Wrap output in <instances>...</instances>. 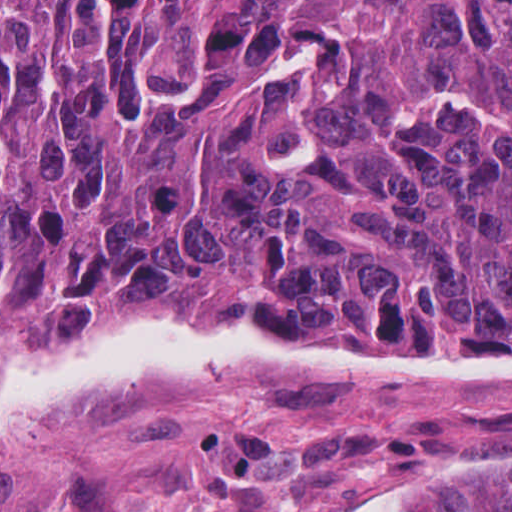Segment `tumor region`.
<instances>
[{"label":"tumor region","mask_w":512,"mask_h":512,"mask_svg":"<svg viewBox=\"0 0 512 512\" xmlns=\"http://www.w3.org/2000/svg\"><path fill=\"white\" fill-rule=\"evenodd\" d=\"M512 338V0H0V318ZM397 512H512L455 470Z\"/></svg>","instance_id":"1"}]
</instances>
